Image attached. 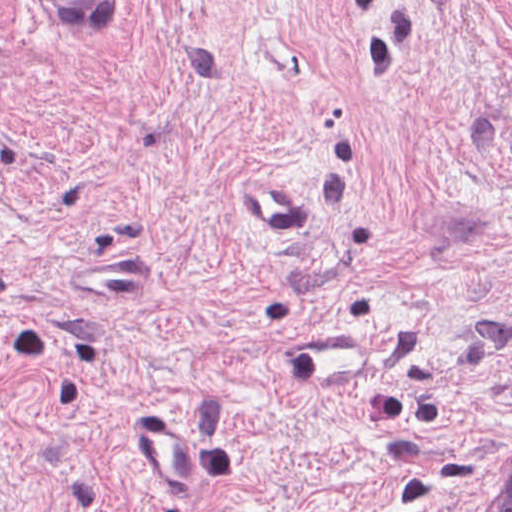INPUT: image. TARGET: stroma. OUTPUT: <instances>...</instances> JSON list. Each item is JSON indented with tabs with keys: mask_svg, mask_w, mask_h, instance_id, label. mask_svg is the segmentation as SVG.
<instances>
[{
	"mask_svg": "<svg viewBox=\"0 0 512 512\" xmlns=\"http://www.w3.org/2000/svg\"><path fill=\"white\" fill-rule=\"evenodd\" d=\"M512 0H0V512H490Z\"/></svg>",
	"mask_w": 512,
	"mask_h": 512,
	"instance_id": "1",
	"label": "stroma"
}]
</instances>
